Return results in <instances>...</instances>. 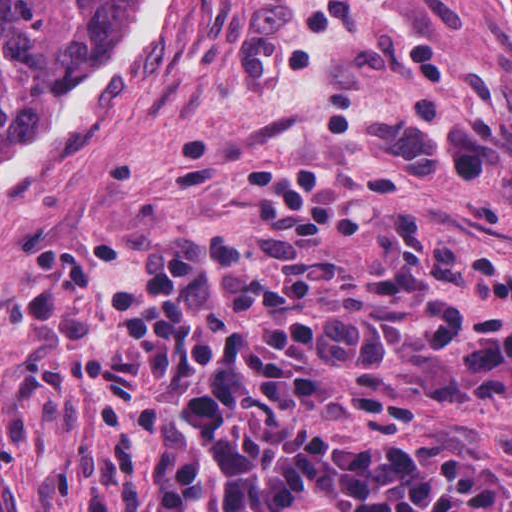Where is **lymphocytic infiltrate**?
Here are the masks:
<instances>
[{"mask_svg": "<svg viewBox=\"0 0 512 512\" xmlns=\"http://www.w3.org/2000/svg\"><path fill=\"white\" fill-rule=\"evenodd\" d=\"M263 229L139 243L80 338L100 470L84 512H512L477 448L411 441L423 398L512 395L500 257L306 163L236 161Z\"/></svg>", "mask_w": 512, "mask_h": 512, "instance_id": "f902f5d3", "label": "lymphocytic infiltrate"}]
</instances>
